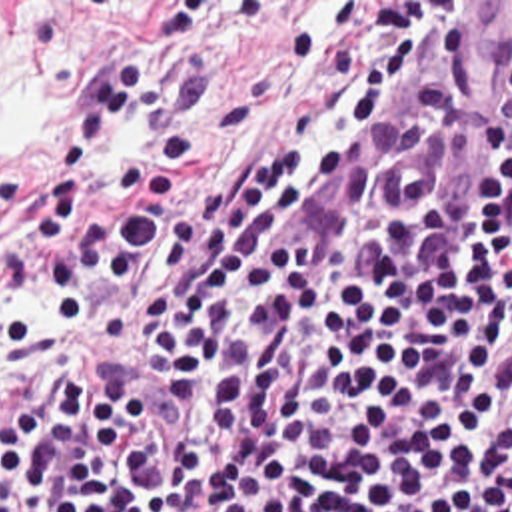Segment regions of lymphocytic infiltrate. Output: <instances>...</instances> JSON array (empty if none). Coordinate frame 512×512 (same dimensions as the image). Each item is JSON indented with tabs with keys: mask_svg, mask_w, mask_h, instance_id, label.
I'll list each match as a JSON object with an SVG mask.
<instances>
[{
	"mask_svg": "<svg viewBox=\"0 0 512 512\" xmlns=\"http://www.w3.org/2000/svg\"><path fill=\"white\" fill-rule=\"evenodd\" d=\"M209 14L169 2L157 44L77 98L27 228L37 294L77 327L101 282L169 254L133 337L185 437L93 349L19 393L0 373V512H512V112L472 238L424 230L436 194L410 212L372 198L348 246L302 228L446 34L398 42L268 158L183 200L167 162L117 158L137 200L77 242L75 192L119 130L195 158L211 60L171 68Z\"/></svg>",
	"mask_w": 512,
	"mask_h": 512,
	"instance_id": "f902f5d3",
	"label": "lymphocytic infiltrate"
}]
</instances>
